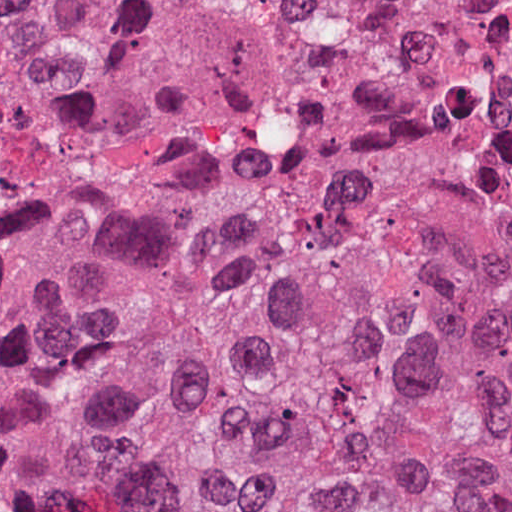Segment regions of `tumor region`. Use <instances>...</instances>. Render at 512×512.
I'll return each mask as SVG.
<instances>
[{
	"instance_id": "1",
	"label": "tumor region",
	"mask_w": 512,
	"mask_h": 512,
	"mask_svg": "<svg viewBox=\"0 0 512 512\" xmlns=\"http://www.w3.org/2000/svg\"><path fill=\"white\" fill-rule=\"evenodd\" d=\"M248 197L0 233V483L30 512H512V0H278ZM134 0H0V90Z\"/></svg>"
}]
</instances>
